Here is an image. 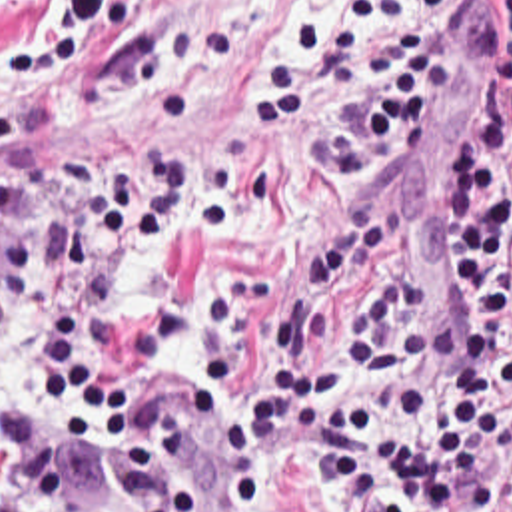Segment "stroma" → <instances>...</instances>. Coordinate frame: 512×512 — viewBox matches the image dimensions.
Masks as SVG:
<instances>
[{
  "label": "stroma",
  "instance_id": "1",
  "mask_svg": "<svg viewBox=\"0 0 512 512\" xmlns=\"http://www.w3.org/2000/svg\"><path fill=\"white\" fill-rule=\"evenodd\" d=\"M345 1L0 0V163L16 173V205L0 225V243L14 227H34L48 235L50 249L56 175L68 151L84 145L112 163H131L151 149L239 159L265 197V221L245 247L203 233L173 235L151 249L129 291L114 299V329L153 305L185 303L183 353L133 359L110 404L88 418L62 392L56 414L28 396L6 402L30 400L56 432L80 442L82 480L66 512H137L131 484L110 452L112 410L137 388L189 375L215 380L217 434L175 462L195 484L199 512H213L221 476L231 470L223 424H239L253 440L303 436L247 428L239 394L319 363L347 379V325L371 303L385 273L353 271L311 301L305 293L307 265L347 221L373 219L385 245L425 271L437 321L451 333L461 327L453 143L489 69L493 39L419 127L407 153L373 171L333 173L331 119L345 97L397 63L385 59L391 27L359 29L329 93L277 133L255 119L253 63L263 51L287 65L293 55L279 29L339 13ZM435 17H477L499 31V0H449L403 21ZM20 331L32 337L26 319ZM251 512H333V484L289 476L257 492ZM495 512H512V494Z\"/></svg>",
  "mask_w": 512,
  "mask_h": 512
}]
</instances>
